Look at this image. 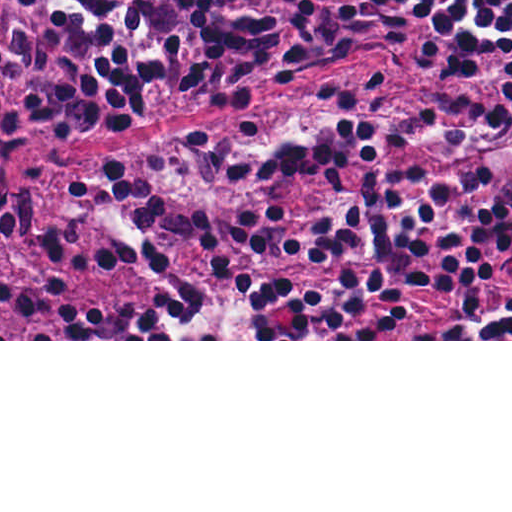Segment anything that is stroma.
<instances>
[{"mask_svg":"<svg viewBox=\"0 0 512 512\" xmlns=\"http://www.w3.org/2000/svg\"><path fill=\"white\" fill-rule=\"evenodd\" d=\"M435 0H420L414 31L402 40L359 52L345 64L304 78L291 86H264L234 92L178 94L113 107L61 139L43 135L11 148L6 176L30 201L25 236L0 239V279L38 283L47 274L44 232L73 222L78 243L77 273L71 286L74 323L71 339L53 302L34 322L0 295V341H512V339H422L431 328L484 326L512 301V266L493 277L471 311L457 315L452 292L432 290L413 304L412 322L385 339H91L98 309L120 314L148 310L156 294L187 280L214 277V258L202 245L182 247L167 266L106 262L103 232L79 199L72 177L150 148L211 129L268 107L258 132L239 138H207L169 161L155 181L171 200H213V235L235 252L238 216L268 207L328 211L354 204L367 177L402 173H441L472 166L463 154H435L423 148H381L365 157L343 184L304 175H283L236 185V161L242 149L280 136L310 131L326 119L349 115L381 123L452 117L488 106L503 87L512 56L479 71H465L495 42L512 34V19L481 42L465 65L441 69L425 55L427 21ZM381 73H420L385 81L364 106L343 107L328 95ZM230 275L285 290H316L353 274L350 264H317L262 255L232 261Z\"/></svg>","mask_w":512,"mask_h":512,"instance_id":"1","label":"stroma"}]
</instances>
